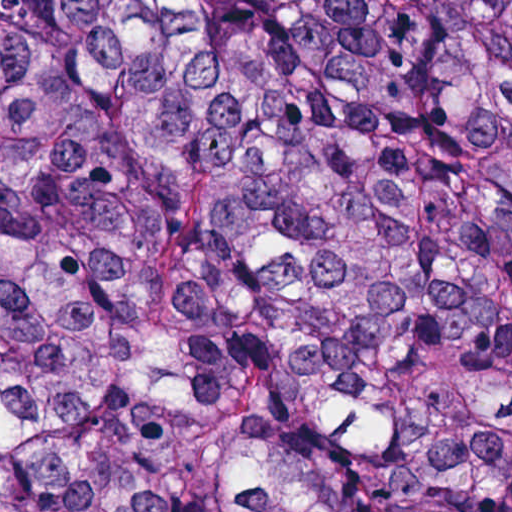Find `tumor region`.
<instances>
[{"label":"tumor region","mask_w":512,"mask_h":512,"mask_svg":"<svg viewBox=\"0 0 512 512\" xmlns=\"http://www.w3.org/2000/svg\"><path fill=\"white\" fill-rule=\"evenodd\" d=\"M0 512H512V0H0Z\"/></svg>","instance_id":"1"}]
</instances>
